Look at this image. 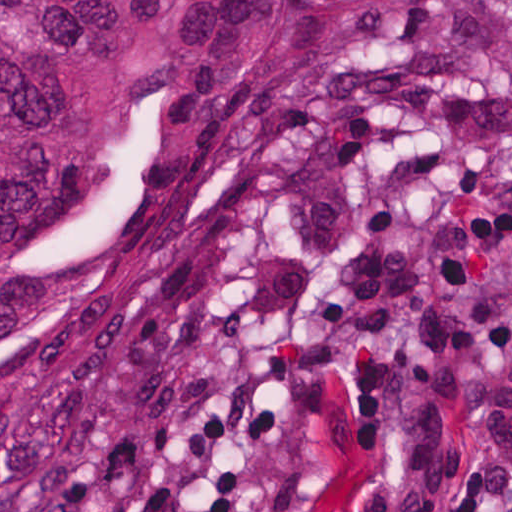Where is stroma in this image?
Listing matches in <instances>:
<instances>
[{"label": "stroma", "instance_id": "35a3bbf8", "mask_svg": "<svg viewBox=\"0 0 512 512\" xmlns=\"http://www.w3.org/2000/svg\"><path fill=\"white\" fill-rule=\"evenodd\" d=\"M496 456L512 0H420L392 78L201 190L116 404L38 512H448Z\"/></svg>", "mask_w": 512, "mask_h": 512}]
</instances>
